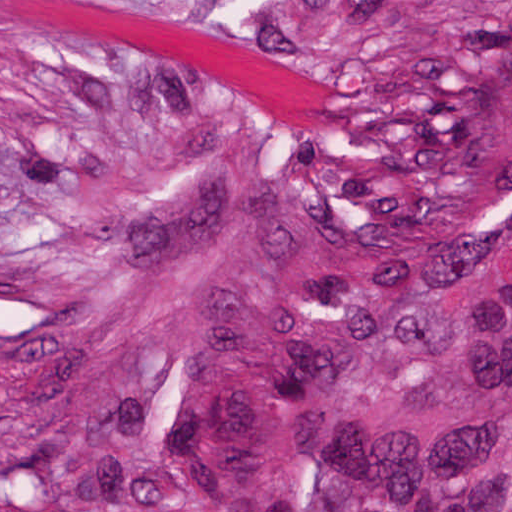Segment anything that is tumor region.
Returning <instances> with one entry per match:
<instances>
[{
	"mask_svg": "<svg viewBox=\"0 0 512 512\" xmlns=\"http://www.w3.org/2000/svg\"><path fill=\"white\" fill-rule=\"evenodd\" d=\"M326 133L1 329V512H512V0H384Z\"/></svg>",
	"mask_w": 512,
	"mask_h": 512,
	"instance_id": "obj_1",
	"label": "tumor region"
}]
</instances>
